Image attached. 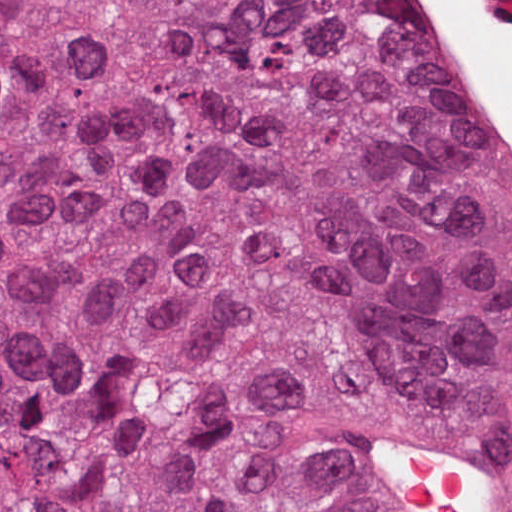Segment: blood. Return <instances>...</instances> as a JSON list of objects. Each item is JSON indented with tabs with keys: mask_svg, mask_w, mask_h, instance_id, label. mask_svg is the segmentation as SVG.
<instances>
[{
	"mask_svg": "<svg viewBox=\"0 0 512 512\" xmlns=\"http://www.w3.org/2000/svg\"><path fill=\"white\" fill-rule=\"evenodd\" d=\"M403 447L395 472L406 495L437 512H476L475 485L466 473Z\"/></svg>",
	"mask_w": 512,
	"mask_h": 512,
	"instance_id": "1",
	"label": "blood"
}]
</instances>
